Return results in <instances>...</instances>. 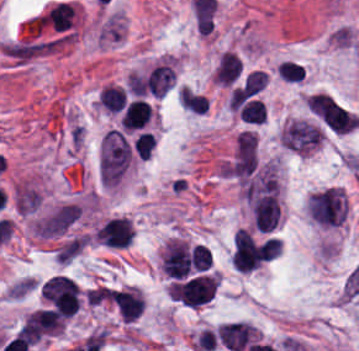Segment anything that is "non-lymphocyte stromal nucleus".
<instances>
[{
    "label": "non-lymphocyte stromal nucleus",
    "mask_w": 359,
    "mask_h": 351,
    "mask_svg": "<svg viewBox=\"0 0 359 351\" xmlns=\"http://www.w3.org/2000/svg\"><path fill=\"white\" fill-rule=\"evenodd\" d=\"M240 200L252 226L271 231L280 219L279 182L276 166L264 164L239 187Z\"/></svg>",
    "instance_id": "1"
},
{
    "label": "non-lymphocyte stromal nucleus",
    "mask_w": 359,
    "mask_h": 351,
    "mask_svg": "<svg viewBox=\"0 0 359 351\" xmlns=\"http://www.w3.org/2000/svg\"><path fill=\"white\" fill-rule=\"evenodd\" d=\"M132 157V148L122 133L107 130L100 141L99 175L101 186L114 187Z\"/></svg>",
    "instance_id": "2"
},
{
    "label": "non-lymphocyte stromal nucleus",
    "mask_w": 359,
    "mask_h": 351,
    "mask_svg": "<svg viewBox=\"0 0 359 351\" xmlns=\"http://www.w3.org/2000/svg\"><path fill=\"white\" fill-rule=\"evenodd\" d=\"M258 137L249 130L239 132L228 160L227 174L232 180L245 181L255 172Z\"/></svg>",
    "instance_id": "3"
},
{
    "label": "non-lymphocyte stromal nucleus",
    "mask_w": 359,
    "mask_h": 351,
    "mask_svg": "<svg viewBox=\"0 0 359 351\" xmlns=\"http://www.w3.org/2000/svg\"><path fill=\"white\" fill-rule=\"evenodd\" d=\"M217 341L230 351H241L255 338V331L246 321H233L215 329Z\"/></svg>",
    "instance_id": "4"
},
{
    "label": "non-lymphocyte stromal nucleus",
    "mask_w": 359,
    "mask_h": 351,
    "mask_svg": "<svg viewBox=\"0 0 359 351\" xmlns=\"http://www.w3.org/2000/svg\"><path fill=\"white\" fill-rule=\"evenodd\" d=\"M85 244V236L82 235L70 238L65 241L58 251L57 259L59 263L66 264L68 261H70L72 258H74L80 253Z\"/></svg>",
    "instance_id": "5"
}]
</instances>
